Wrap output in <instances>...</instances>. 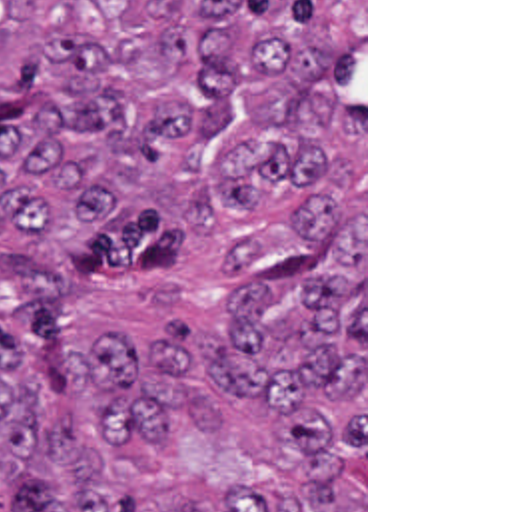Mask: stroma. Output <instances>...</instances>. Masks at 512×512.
I'll return each instance as SVG.
<instances>
[{
	"label": "stroma",
	"instance_id": "obj_1",
	"mask_svg": "<svg viewBox=\"0 0 512 512\" xmlns=\"http://www.w3.org/2000/svg\"><path fill=\"white\" fill-rule=\"evenodd\" d=\"M342 110L364 120V375H366V487L364 512H368V0H364V54L352 68L340 96Z\"/></svg>",
	"mask_w": 512,
	"mask_h": 512
}]
</instances>
